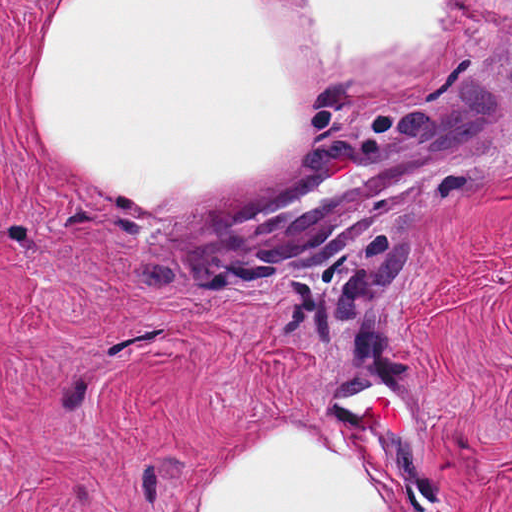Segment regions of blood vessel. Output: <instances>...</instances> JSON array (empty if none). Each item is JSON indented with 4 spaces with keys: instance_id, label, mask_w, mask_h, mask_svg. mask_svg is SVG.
Returning <instances> with one entry per match:
<instances>
[{
    "instance_id": "blood-vessel-1",
    "label": "blood vessel",
    "mask_w": 512,
    "mask_h": 512,
    "mask_svg": "<svg viewBox=\"0 0 512 512\" xmlns=\"http://www.w3.org/2000/svg\"><path fill=\"white\" fill-rule=\"evenodd\" d=\"M488 139L490 106L461 101L325 157L245 202L203 209L185 234L183 256L247 263L278 247L328 239L369 220L431 167Z\"/></svg>"
}]
</instances>
